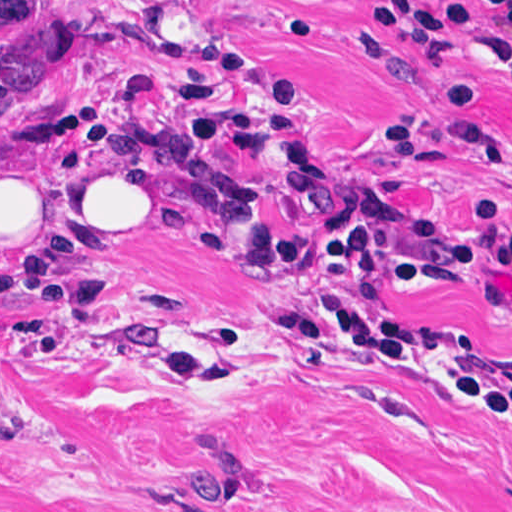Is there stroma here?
Listing matches in <instances>:
<instances>
[{"mask_svg": "<svg viewBox=\"0 0 512 512\" xmlns=\"http://www.w3.org/2000/svg\"><path fill=\"white\" fill-rule=\"evenodd\" d=\"M453 11L480 0H419ZM381 0H0V151L129 172L166 220L145 240L15 255L0 237V512H512V415L448 383L512 377V302L491 266L409 289L383 274L336 293L412 333L401 366L288 339L285 303L319 293L312 255L335 230L410 235L427 216L466 235L477 211L512 226V80L473 7L435 58L379 17ZM170 10L243 78L219 87L257 118L239 158L196 134L176 87L208 82L164 46ZM307 34L280 33L295 13ZM387 54H350L358 27ZM274 99L341 178L301 223L273 135ZM255 190L293 257L272 271L198 253L218 200ZM477 210V211H476ZM2 227V226H0ZM244 458L231 503L184 495L180 457L203 424Z\"/></svg>", "mask_w": 512, "mask_h": 512, "instance_id": "35a3bbf8", "label": "stroma"}]
</instances>
